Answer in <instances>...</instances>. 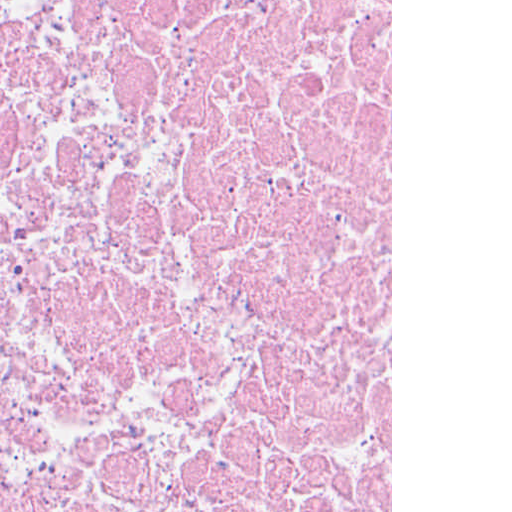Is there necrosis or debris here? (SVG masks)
Listing matches in <instances>:
<instances>
[{"label": "necrosis or debris", "instance_id": "4bbe7bcc", "mask_svg": "<svg viewBox=\"0 0 512 512\" xmlns=\"http://www.w3.org/2000/svg\"><path fill=\"white\" fill-rule=\"evenodd\" d=\"M0 512H391V0H0Z\"/></svg>", "mask_w": 512, "mask_h": 512}]
</instances>
